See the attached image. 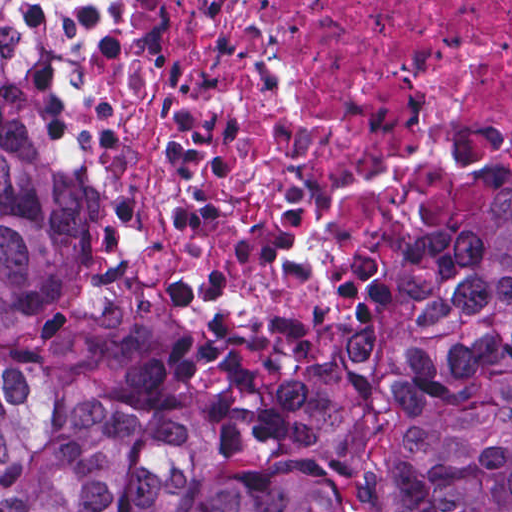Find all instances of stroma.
Instances as JSON below:
<instances>
[{"label":"stroma","instance_id":"1","mask_svg":"<svg viewBox=\"0 0 512 512\" xmlns=\"http://www.w3.org/2000/svg\"><path fill=\"white\" fill-rule=\"evenodd\" d=\"M40 65L50 141L78 185L88 241L81 287L44 324L0 334V355L90 377L160 411L213 417L280 397L358 346L411 256L454 212L512 185V139L454 163L448 187L412 218L396 259L375 263L353 296L331 290L336 228L372 175L351 179L321 235L269 283L245 294L204 290L182 258L143 246L96 157V74L119 24L78 19L66 0H0Z\"/></svg>","mask_w":512,"mask_h":512}]
</instances>
